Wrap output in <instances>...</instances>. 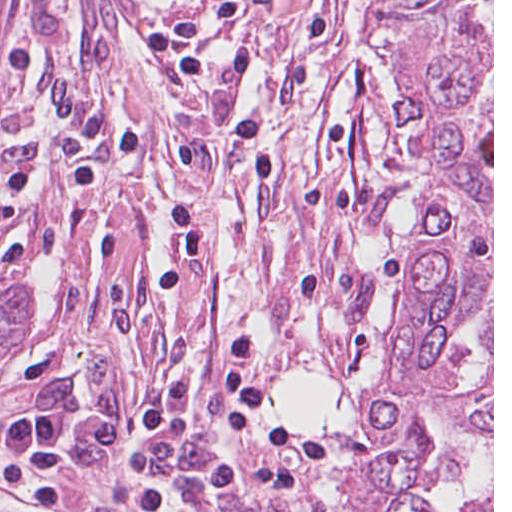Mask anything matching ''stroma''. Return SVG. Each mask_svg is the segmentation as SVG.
<instances>
[{
	"label": "stroma",
	"instance_id": "1",
	"mask_svg": "<svg viewBox=\"0 0 512 512\" xmlns=\"http://www.w3.org/2000/svg\"><path fill=\"white\" fill-rule=\"evenodd\" d=\"M189 201L207 256L167 294L152 284ZM38 309L0 361V428L63 406L85 429L156 386L189 380L171 463L260 466L272 448L222 423L219 356L253 333L274 400L302 368L327 384L202 0H10L0 38V299L23 279ZM292 486L194 492L177 512H368L343 436L296 437ZM138 436L88 465L72 497L145 512ZM0 486V512H20Z\"/></svg>",
	"mask_w": 512,
	"mask_h": 512
}]
</instances>
